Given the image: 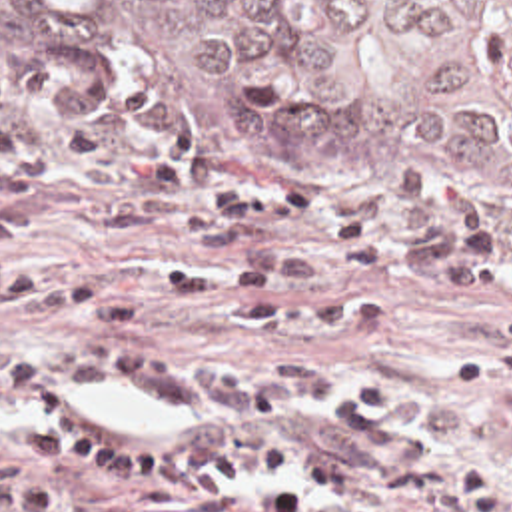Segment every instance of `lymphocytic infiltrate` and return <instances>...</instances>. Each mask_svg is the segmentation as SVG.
I'll use <instances>...</instances> for the list:
<instances>
[{
  "instance_id": "obj_1",
  "label": "lymphocytic infiltrate",
  "mask_w": 512,
  "mask_h": 512,
  "mask_svg": "<svg viewBox=\"0 0 512 512\" xmlns=\"http://www.w3.org/2000/svg\"><path fill=\"white\" fill-rule=\"evenodd\" d=\"M361 200L377 218L403 226L407 270L421 282L463 286L491 320L485 346L455 358L449 380H512V240L499 246L481 194L425 170H397L363 182Z\"/></svg>"
}]
</instances>
